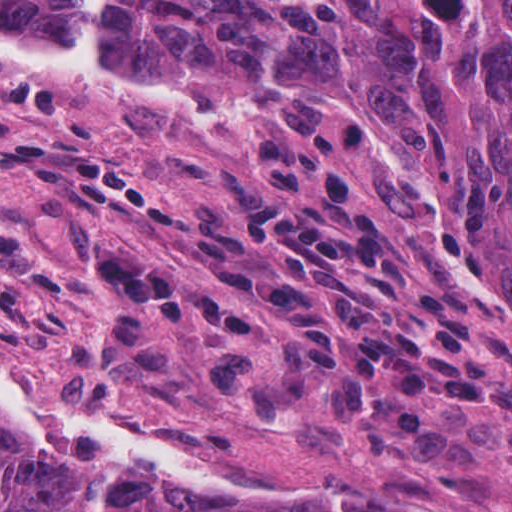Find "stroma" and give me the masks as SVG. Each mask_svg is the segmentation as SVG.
Masks as SVG:
<instances>
[{
  "mask_svg": "<svg viewBox=\"0 0 512 512\" xmlns=\"http://www.w3.org/2000/svg\"><path fill=\"white\" fill-rule=\"evenodd\" d=\"M111 52L206 98L103 112L0 90V370L204 448L250 489L125 476L512 512V297L453 174L362 100Z\"/></svg>",
  "mask_w": 512,
  "mask_h": 512,
  "instance_id": "stroma-1",
  "label": "stroma"
}]
</instances>
